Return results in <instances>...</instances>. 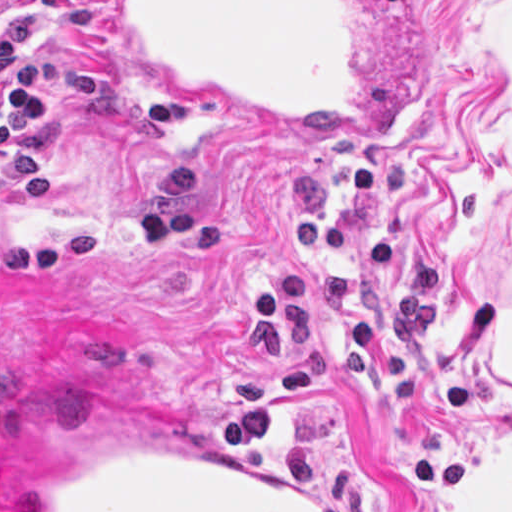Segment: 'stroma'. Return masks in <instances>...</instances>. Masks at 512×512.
Wrapping results in <instances>:
<instances>
[{"label":"stroma","instance_id":"35a3bbf8","mask_svg":"<svg viewBox=\"0 0 512 512\" xmlns=\"http://www.w3.org/2000/svg\"><path fill=\"white\" fill-rule=\"evenodd\" d=\"M139 103L107 0H18ZM53 113L47 198L0 177V512L141 432L338 512H512V0H413L390 145L187 101L177 129Z\"/></svg>","mask_w":512,"mask_h":512}]
</instances>
